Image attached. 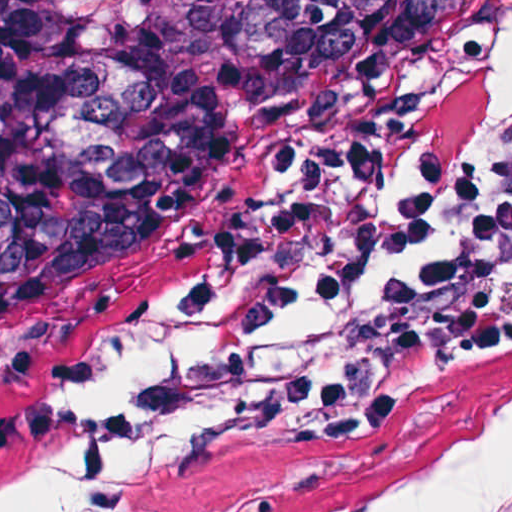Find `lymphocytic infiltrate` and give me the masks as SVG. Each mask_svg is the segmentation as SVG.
<instances>
[{
  "label": "lymphocytic infiltrate",
  "instance_id": "obj_1",
  "mask_svg": "<svg viewBox=\"0 0 512 512\" xmlns=\"http://www.w3.org/2000/svg\"><path fill=\"white\" fill-rule=\"evenodd\" d=\"M384 154L320 163L218 223L168 295L200 343L124 408L38 399L0 410V454L76 457L66 512H123L147 448L212 410L216 430L342 447L376 420L384 369L280 345L300 322L354 321L407 366L488 368L512 354V127L385 199Z\"/></svg>",
  "mask_w": 512,
  "mask_h": 512
}]
</instances>
